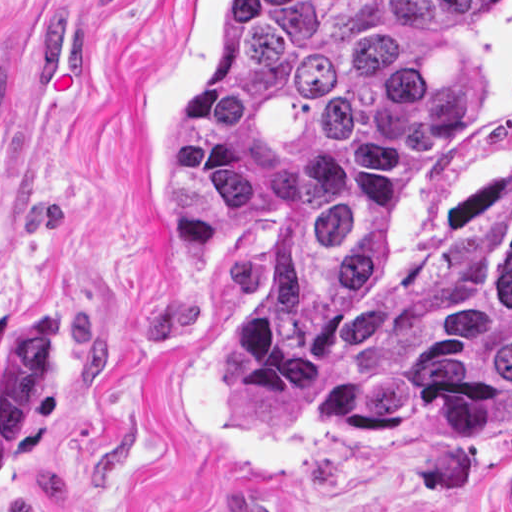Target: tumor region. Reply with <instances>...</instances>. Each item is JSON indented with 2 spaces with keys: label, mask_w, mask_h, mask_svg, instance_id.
Segmentation results:
<instances>
[{
  "label": "tumor region",
  "mask_w": 512,
  "mask_h": 512,
  "mask_svg": "<svg viewBox=\"0 0 512 512\" xmlns=\"http://www.w3.org/2000/svg\"><path fill=\"white\" fill-rule=\"evenodd\" d=\"M509 0H224L159 139L180 275L266 249L214 309L235 429L454 437L512 405V212L429 234L393 281L369 241L395 175L457 121L452 73Z\"/></svg>",
  "instance_id": "tumor-region-1"
}]
</instances>
